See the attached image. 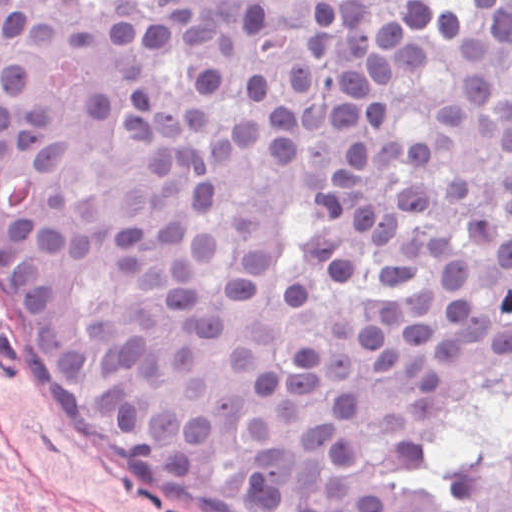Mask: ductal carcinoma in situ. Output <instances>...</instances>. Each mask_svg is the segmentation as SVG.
Instances as JSON below:
<instances>
[{
  "mask_svg": "<svg viewBox=\"0 0 512 512\" xmlns=\"http://www.w3.org/2000/svg\"><path fill=\"white\" fill-rule=\"evenodd\" d=\"M0 329L171 512H512V0H0Z\"/></svg>",
  "mask_w": 512,
  "mask_h": 512,
  "instance_id": "obj_1",
  "label": "ductal carcinoma in situ"
}]
</instances>
